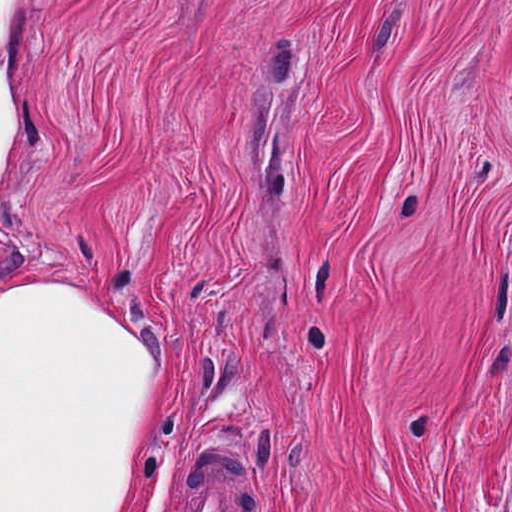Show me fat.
Here are the masks:
<instances>
[{"instance_id":"obj_1","label":"fat","mask_w":512,"mask_h":512,"mask_svg":"<svg viewBox=\"0 0 512 512\" xmlns=\"http://www.w3.org/2000/svg\"><path fill=\"white\" fill-rule=\"evenodd\" d=\"M30 1L0 0V193L28 124ZM156 376L145 333L0 283V512H124Z\"/></svg>"}]
</instances>
